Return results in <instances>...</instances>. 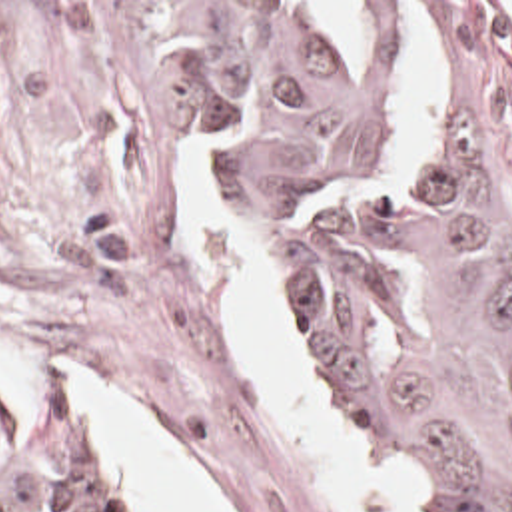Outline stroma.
I'll return each mask as SVG.
<instances>
[{
	"mask_svg": "<svg viewBox=\"0 0 512 512\" xmlns=\"http://www.w3.org/2000/svg\"><path fill=\"white\" fill-rule=\"evenodd\" d=\"M163 2H291L307 22L301 2H395L385 68L371 72L363 62V72H347L385 80V154L355 180L307 198L305 208L381 176L442 120L450 32L424 2L448 6L512 184V0H0V347L65 367L165 443L219 512H339L311 461L269 417L229 337L239 250L211 234L191 256L181 178L201 146L217 144L221 188L263 264L283 333L267 240L291 214L261 206L239 142L187 88ZM405 2H414L438 38L444 96L397 150L387 90L403 54ZM289 355L321 427L399 512H424L359 447ZM0 381L13 387L1 371ZM29 403L93 455L115 512H143L99 465L65 375L45 369L39 399Z\"/></svg>",
	"mask_w": 512,
	"mask_h": 512,
	"instance_id": "1",
	"label": "stroma"
}]
</instances>
